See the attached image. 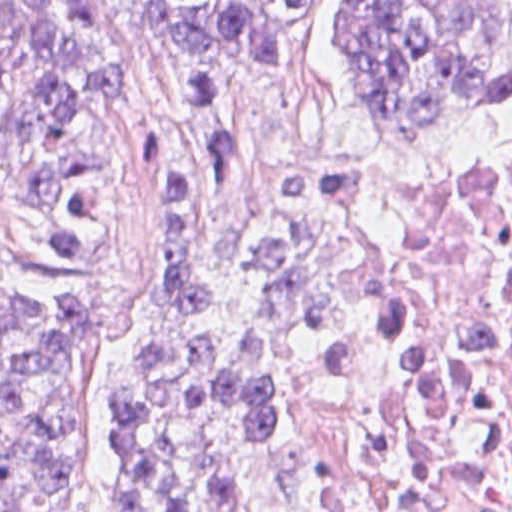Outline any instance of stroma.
I'll list each match as a JSON object with an SVG mask.
<instances>
[{"instance_id": "obj_1", "label": "stroma", "mask_w": 512, "mask_h": 512, "mask_svg": "<svg viewBox=\"0 0 512 512\" xmlns=\"http://www.w3.org/2000/svg\"><path fill=\"white\" fill-rule=\"evenodd\" d=\"M497 1L512 10V0ZM159 130L196 172L206 250L225 253L258 225L294 222L324 266L355 293L354 311L319 344L302 378L287 441L262 485L260 512H311L374 414L390 402L444 426L459 451V476L403 512H462L477 498V465L461 417L442 398L404 393L352 403L332 383L357 334L361 301L347 253L307 210L302 184L361 159H444L498 149L512 143V113L464 138L388 140L362 105L355 0H322L303 38L277 58L209 51L151 26L115 47L76 128L48 154L95 153L114 175L119 223L93 262L74 268L51 262L28 199L0 182V283L70 295L96 322V346L75 393L73 505L61 512H119L114 407L122 379L160 321V241L141 177L144 134ZM20 191L27 197V188ZM0 456H9L1 432Z\"/></svg>"}]
</instances>
